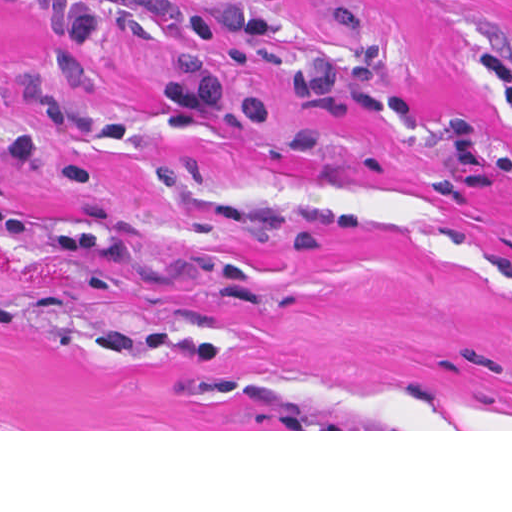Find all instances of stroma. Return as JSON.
I'll list each match as a JSON object with an SVG mask.
<instances>
[{
	"label": "stroma",
	"mask_w": 512,
	"mask_h": 512,
	"mask_svg": "<svg viewBox=\"0 0 512 512\" xmlns=\"http://www.w3.org/2000/svg\"><path fill=\"white\" fill-rule=\"evenodd\" d=\"M71 15L0 0V431H512V0H284L207 115Z\"/></svg>",
	"instance_id": "1"
}]
</instances>
